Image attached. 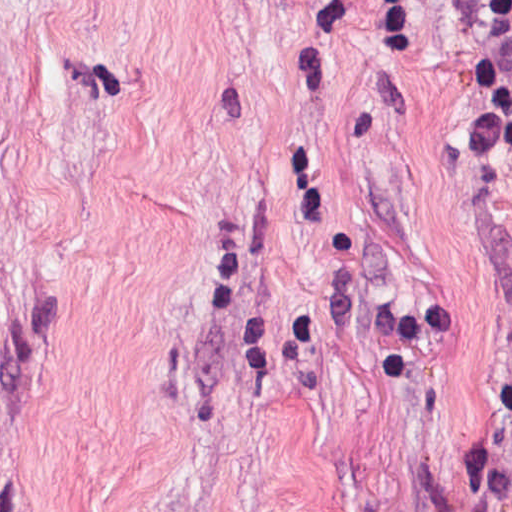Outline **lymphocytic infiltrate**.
I'll use <instances>...</instances> for the list:
<instances>
[{"mask_svg":"<svg viewBox=\"0 0 512 512\" xmlns=\"http://www.w3.org/2000/svg\"><path fill=\"white\" fill-rule=\"evenodd\" d=\"M483 89L487 135L512 160V0H443ZM494 512H512V352L494 373Z\"/></svg>","mask_w":512,"mask_h":512,"instance_id":"f902f5d3","label":"lymphocytic infiltrate"}]
</instances>
